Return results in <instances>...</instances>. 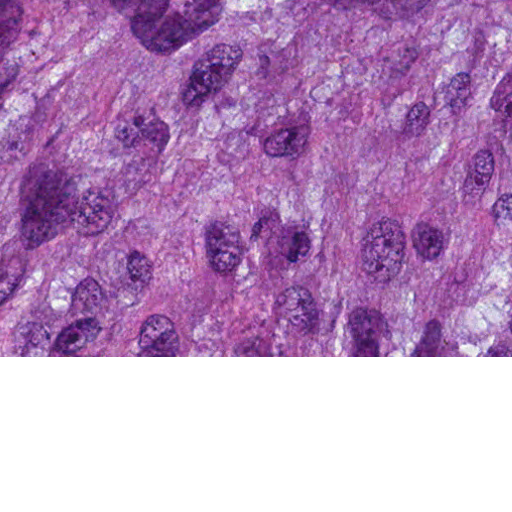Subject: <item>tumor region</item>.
Returning a JSON list of instances; mask_svg holds the SVG:
<instances>
[{
  "mask_svg": "<svg viewBox=\"0 0 512 512\" xmlns=\"http://www.w3.org/2000/svg\"><path fill=\"white\" fill-rule=\"evenodd\" d=\"M0 356H512V0H0Z\"/></svg>",
  "mask_w": 512,
  "mask_h": 512,
  "instance_id": "1",
  "label": "tumor region"
}]
</instances>
